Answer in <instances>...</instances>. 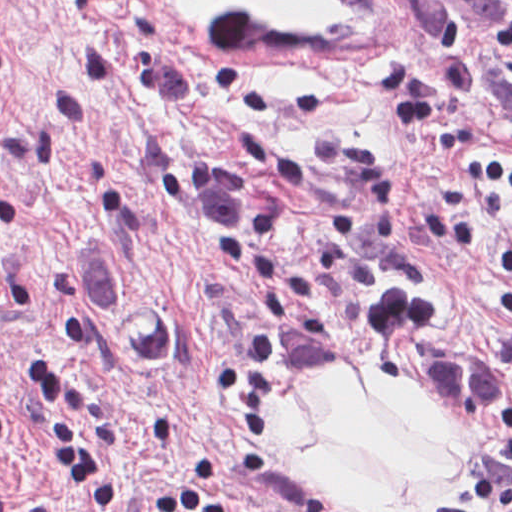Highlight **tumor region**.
Returning a JSON list of instances; mask_svg holds the SVG:
<instances>
[{
    "label": "tumor region",
    "instance_id": "tumor-region-1",
    "mask_svg": "<svg viewBox=\"0 0 512 512\" xmlns=\"http://www.w3.org/2000/svg\"><path fill=\"white\" fill-rule=\"evenodd\" d=\"M427 40L456 89L512 142V0H415ZM97 343L130 368H162L177 328L146 305L106 308ZM404 379L422 413L458 453L482 512H512V350L428 341L408 350Z\"/></svg>",
    "mask_w": 512,
    "mask_h": 512
}]
</instances>
